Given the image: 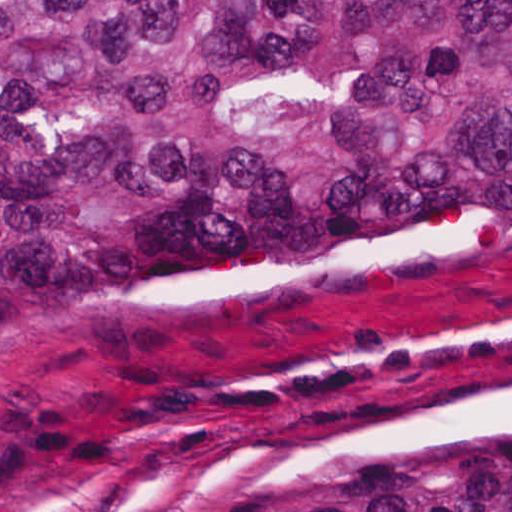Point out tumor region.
<instances>
[{
	"instance_id": "tumor-region-1",
	"label": "tumor region",
	"mask_w": 512,
	"mask_h": 512,
	"mask_svg": "<svg viewBox=\"0 0 512 512\" xmlns=\"http://www.w3.org/2000/svg\"><path fill=\"white\" fill-rule=\"evenodd\" d=\"M507 192L512 0H1V322L127 305L223 245ZM31 512H512V420Z\"/></svg>"
}]
</instances>
